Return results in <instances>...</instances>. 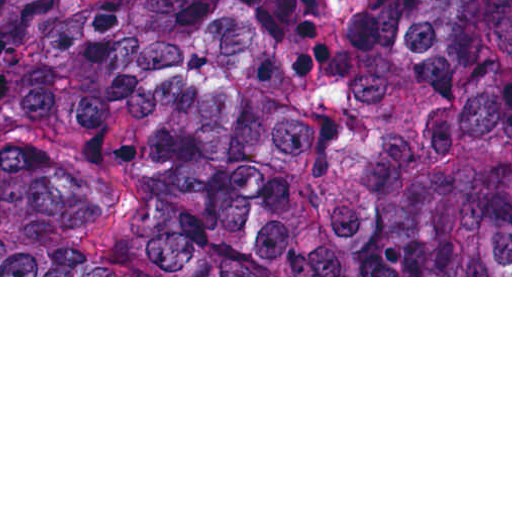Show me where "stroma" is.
<instances>
[{"instance_id":"35a3bbf8","label":"stroma","mask_w":512,"mask_h":512,"mask_svg":"<svg viewBox=\"0 0 512 512\" xmlns=\"http://www.w3.org/2000/svg\"><path fill=\"white\" fill-rule=\"evenodd\" d=\"M0 277H512V268H94Z\"/></svg>"}]
</instances>
